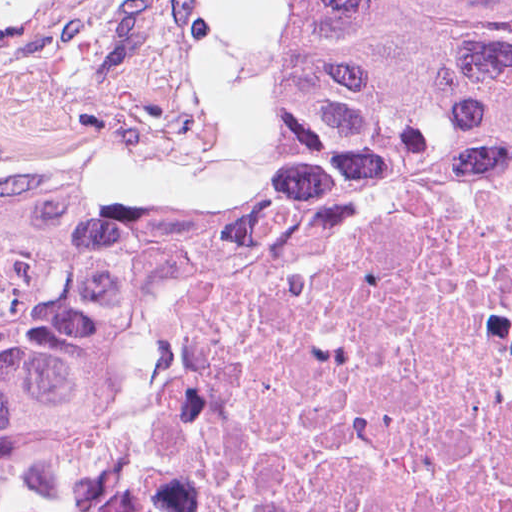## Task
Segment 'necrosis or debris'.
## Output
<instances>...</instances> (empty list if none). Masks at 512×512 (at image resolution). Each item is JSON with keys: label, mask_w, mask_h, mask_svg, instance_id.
<instances>
[{"label": "necrosis or debris", "mask_w": 512, "mask_h": 512, "mask_svg": "<svg viewBox=\"0 0 512 512\" xmlns=\"http://www.w3.org/2000/svg\"><path fill=\"white\" fill-rule=\"evenodd\" d=\"M142 512H512V129L189 348Z\"/></svg>", "instance_id": "4bbe7bcc"}]
</instances>
